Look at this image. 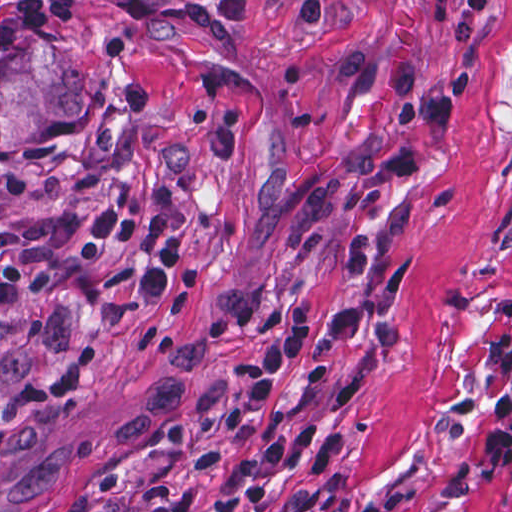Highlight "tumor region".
<instances>
[{
    "instance_id": "e687c5a6",
    "label": "tumor region",
    "mask_w": 512,
    "mask_h": 512,
    "mask_svg": "<svg viewBox=\"0 0 512 512\" xmlns=\"http://www.w3.org/2000/svg\"><path fill=\"white\" fill-rule=\"evenodd\" d=\"M91 107V83L61 42L32 37L0 72V152L25 146L49 119L78 118Z\"/></svg>"
}]
</instances>
